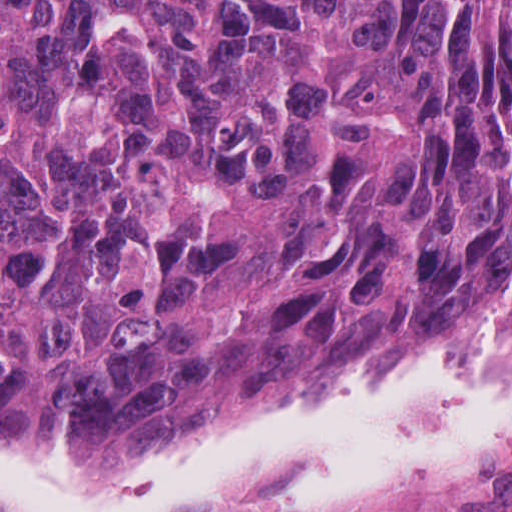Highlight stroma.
Here are the masks:
<instances>
[{"instance_id":"obj_1","label":"stroma","mask_w":512,"mask_h":512,"mask_svg":"<svg viewBox=\"0 0 512 512\" xmlns=\"http://www.w3.org/2000/svg\"><path fill=\"white\" fill-rule=\"evenodd\" d=\"M487 321H512V318L491 315L482 323ZM446 337L448 336L436 338L418 348L430 346ZM289 419L281 420L253 416L231 433L198 429L167 435L137 451L104 447L77 453H73L47 439L15 434L1 427L0 0V512L1 438L55 468L90 477L135 458L161 451L203 444H230ZM306 512H512V440L496 447L469 469L449 477L428 482L373 489L334 506Z\"/></svg>"}]
</instances>
